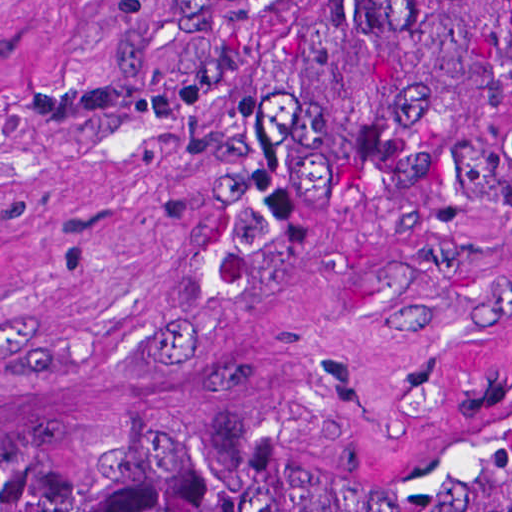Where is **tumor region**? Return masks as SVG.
I'll list each match as a JSON object with an SVG mask.
<instances>
[{"label":"tumor region","mask_w":512,"mask_h":512,"mask_svg":"<svg viewBox=\"0 0 512 512\" xmlns=\"http://www.w3.org/2000/svg\"><path fill=\"white\" fill-rule=\"evenodd\" d=\"M137 82L237 203V366L285 372L375 182L508 135L489 0H360V35L279 51L269 0H145ZM0 512H512V415L398 481L279 434H0Z\"/></svg>","instance_id":"tumor-region-1"}]
</instances>
